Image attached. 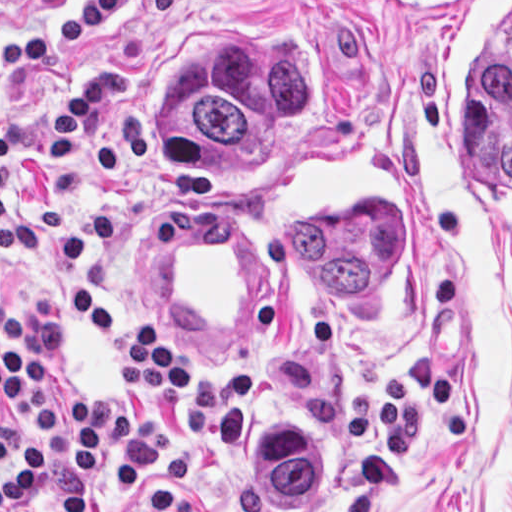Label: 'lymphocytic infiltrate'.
Masks as SVG:
<instances>
[{
    "label": "lymphocytic infiltrate",
    "mask_w": 512,
    "mask_h": 512,
    "mask_svg": "<svg viewBox=\"0 0 512 512\" xmlns=\"http://www.w3.org/2000/svg\"><path fill=\"white\" fill-rule=\"evenodd\" d=\"M127 73L112 66L91 73L71 89L64 113L53 118L47 147L63 164L89 171L102 185H124L152 146V130L134 110L121 112L103 143L79 146L93 108L124 99ZM71 324L84 336L106 344L123 377L121 402L83 406L44 404L51 384V360L44 349L15 347L1 352V404L16 416V443L10 476L1 480V512L17 503L39 480L46 436L52 425L65 441L73 469L52 497V512H85L89 487L105 464L107 489L136 486L171 455V417L149 402L174 396L189 385V353L149 323L110 315L89 291L64 296Z\"/></svg>",
    "instance_id": "lymphocytic-infiltrate-1"
}]
</instances>
